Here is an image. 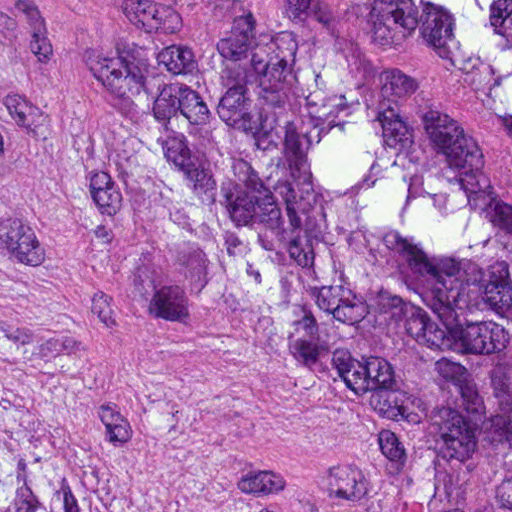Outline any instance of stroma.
<instances>
[{
    "mask_svg": "<svg viewBox=\"0 0 512 512\" xmlns=\"http://www.w3.org/2000/svg\"><path fill=\"white\" fill-rule=\"evenodd\" d=\"M304 13L512 203V133L379 0H0V372L82 438L97 477L176 512H382L392 462L244 343L225 288L147 269L54 189L82 77L247 6Z\"/></svg>",
    "mask_w": 512,
    "mask_h": 512,
    "instance_id": "35a3bbf8",
    "label": "stroma"
}]
</instances>
